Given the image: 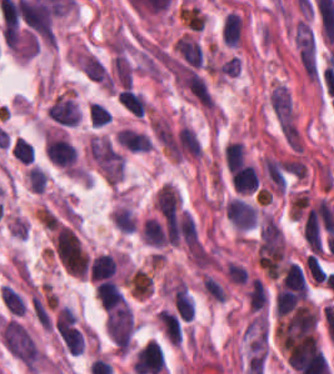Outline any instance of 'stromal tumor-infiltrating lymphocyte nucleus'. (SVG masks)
Masks as SVG:
<instances>
[{
	"mask_svg": "<svg viewBox=\"0 0 334 374\" xmlns=\"http://www.w3.org/2000/svg\"><path fill=\"white\" fill-rule=\"evenodd\" d=\"M96 298L107 311L126 303V299L114 279H101L96 286Z\"/></svg>",
	"mask_w": 334,
	"mask_h": 374,
	"instance_id": "obj_1",
	"label": "stromal tumor-infiltrating lymphocyte nucleus"
},
{
	"mask_svg": "<svg viewBox=\"0 0 334 374\" xmlns=\"http://www.w3.org/2000/svg\"><path fill=\"white\" fill-rule=\"evenodd\" d=\"M117 269L118 261L115 256L112 254H98L90 260L88 278L90 281L114 278Z\"/></svg>",
	"mask_w": 334,
	"mask_h": 374,
	"instance_id": "obj_2",
	"label": "stromal tumor-infiltrating lymphocyte nucleus"
},
{
	"mask_svg": "<svg viewBox=\"0 0 334 374\" xmlns=\"http://www.w3.org/2000/svg\"><path fill=\"white\" fill-rule=\"evenodd\" d=\"M249 312H262L268 304V294L265 284L255 276L250 279L246 292Z\"/></svg>",
	"mask_w": 334,
	"mask_h": 374,
	"instance_id": "obj_3",
	"label": "stromal tumor-infiltrating lymphocyte nucleus"
},
{
	"mask_svg": "<svg viewBox=\"0 0 334 374\" xmlns=\"http://www.w3.org/2000/svg\"><path fill=\"white\" fill-rule=\"evenodd\" d=\"M243 22L236 12H229L222 21L221 37L226 45L238 46L242 41Z\"/></svg>",
	"mask_w": 334,
	"mask_h": 374,
	"instance_id": "obj_4",
	"label": "stromal tumor-infiltrating lymphocyte nucleus"
},
{
	"mask_svg": "<svg viewBox=\"0 0 334 374\" xmlns=\"http://www.w3.org/2000/svg\"><path fill=\"white\" fill-rule=\"evenodd\" d=\"M227 172H236L246 163V149L242 141L230 143L224 150Z\"/></svg>",
	"mask_w": 334,
	"mask_h": 374,
	"instance_id": "obj_5",
	"label": "stromal tumor-infiltrating lymphocyte nucleus"
},
{
	"mask_svg": "<svg viewBox=\"0 0 334 374\" xmlns=\"http://www.w3.org/2000/svg\"><path fill=\"white\" fill-rule=\"evenodd\" d=\"M117 100L131 113L143 116L146 102L142 95L131 88H123L117 95Z\"/></svg>",
	"mask_w": 334,
	"mask_h": 374,
	"instance_id": "obj_6",
	"label": "stromal tumor-infiltrating lymphocyte nucleus"
},
{
	"mask_svg": "<svg viewBox=\"0 0 334 374\" xmlns=\"http://www.w3.org/2000/svg\"><path fill=\"white\" fill-rule=\"evenodd\" d=\"M1 298L9 313L23 315L27 306L14 289L4 284L1 288Z\"/></svg>",
	"mask_w": 334,
	"mask_h": 374,
	"instance_id": "obj_7",
	"label": "stromal tumor-infiltrating lymphocyte nucleus"
},
{
	"mask_svg": "<svg viewBox=\"0 0 334 374\" xmlns=\"http://www.w3.org/2000/svg\"><path fill=\"white\" fill-rule=\"evenodd\" d=\"M11 153L23 164H30L34 160L33 146L23 137H16Z\"/></svg>",
	"mask_w": 334,
	"mask_h": 374,
	"instance_id": "obj_8",
	"label": "stromal tumor-infiltrating lymphocyte nucleus"
},
{
	"mask_svg": "<svg viewBox=\"0 0 334 374\" xmlns=\"http://www.w3.org/2000/svg\"><path fill=\"white\" fill-rule=\"evenodd\" d=\"M88 114L95 126H104L112 121V113L98 102L90 103Z\"/></svg>",
	"mask_w": 334,
	"mask_h": 374,
	"instance_id": "obj_9",
	"label": "stromal tumor-infiltrating lymphocyte nucleus"
}]
</instances>
